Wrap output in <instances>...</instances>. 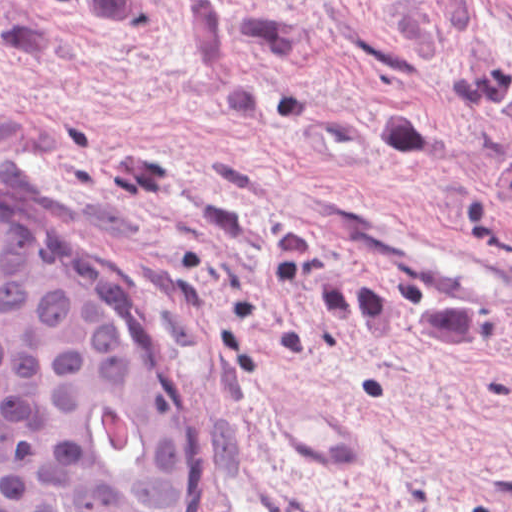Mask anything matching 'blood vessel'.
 Segmentation results:
<instances>
[{
    "mask_svg": "<svg viewBox=\"0 0 512 512\" xmlns=\"http://www.w3.org/2000/svg\"><path fill=\"white\" fill-rule=\"evenodd\" d=\"M298 203L355 244L428 269L482 296H512V264L424 229L352 191L292 194Z\"/></svg>",
    "mask_w": 512,
    "mask_h": 512,
    "instance_id": "blood-vessel-1",
    "label": "blood vessel"
}]
</instances>
